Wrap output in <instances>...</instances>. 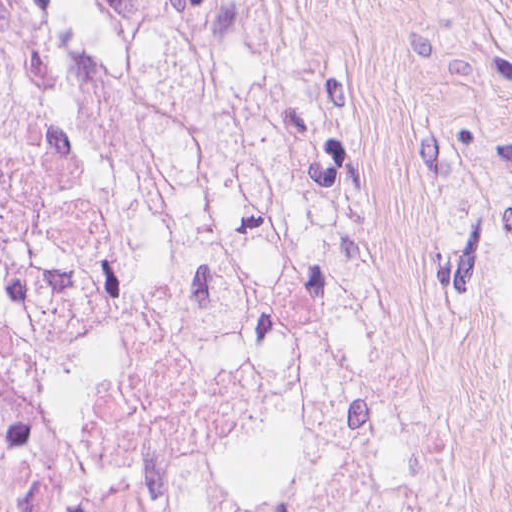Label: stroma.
I'll return each instance as SVG.
<instances>
[{"instance_id": "stroma-1", "label": "stroma", "mask_w": 512, "mask_h": 512, "mask_svg": "<svg viewBox=\"0 0 512 512\" xmlns=\"http://www.w3.org/2000/svg\"><path fill=\"white\" fill-rule=\"evenodd\" d=\"M318 253L399 512H512V0H305Z\"/></svg>"}]
</instances>
